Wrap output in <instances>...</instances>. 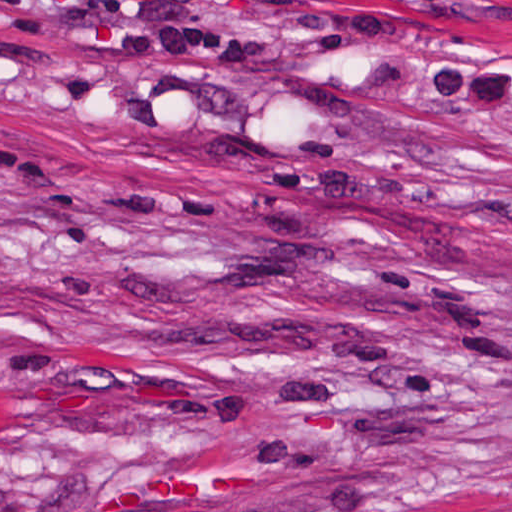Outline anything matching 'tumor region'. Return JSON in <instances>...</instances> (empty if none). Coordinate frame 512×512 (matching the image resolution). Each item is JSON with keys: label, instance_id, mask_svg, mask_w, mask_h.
I'll list each match as a JSON object with an SVG mask.
<instances>
[{"label": "tumor region", "instance_id": "obj_1", "mask_svg": "<svg viewBox=\"0 0 512 512\" xmlns=\"http://www.w3.org/2000/svg\"><path fill=\"white\" fill-rule=\"evenodd\" d=\"M0 512H33L0 485ZM447 512H512V490L503 491Z\"/></svg>", "mask_w": 512, "mask_h": 512}]
</instances>
